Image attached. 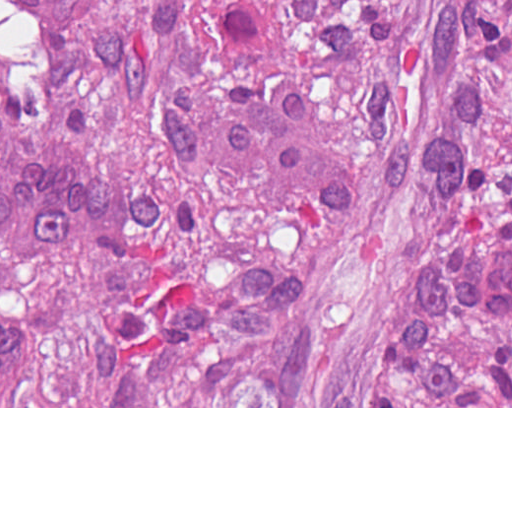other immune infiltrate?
<instances>
[{"instance_id": "other-immune-infiltrate-1", "label": "other immune infiltrate", "mask_w": 512, "mask_h": 512, "mask_svg": "<svg viewBox=\"0 0 512 512\" xmlns=\"http://www.w3.org/2000/svg\"><path fill=\"white\" fill-rule=\"evenodd\" d=\"M0 161V251L12 258H63L93 242L98 179L59 141ZM462 282L484 309L512 319V244L470 247ZM32 356L27 327L0 312V406H12Z\"/></svg>"}]
</instances>
